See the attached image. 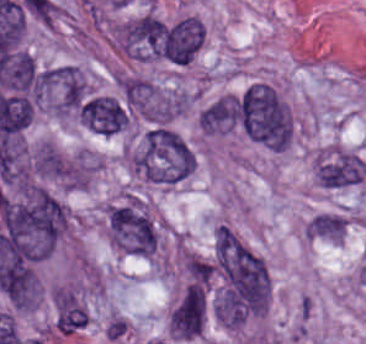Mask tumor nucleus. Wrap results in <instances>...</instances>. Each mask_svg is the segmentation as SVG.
<instances>
[{
	"label": "tumor nucleus",
	"mask_w": 366,
	"mask_h": 344,
	"mask_svg": "<svg viewBox=\"0 0 366 344\" xmlns=\"http://www.w3.org/2000/svg\"><path fill=\"white\" fill-rule=\"evenodd\" d=\"M235 121L249 139L271 150H285L292 135L291 110L271 84L255 82L235 98Z\"/></svg>",
	"instance_id": "tumor-nucleus-1"
},
{
	"label": "tumor nucleus",
	"mask_w": 366,
	"mask_h": 344,
	"mask_svg": "<svg viewBox=\"0 0 366 344\" xmlns=\"http://www.w3.org/2000/svg\"><path fill=\"white\" fill-rule=\"evenodd\" d=\"M129 168L153 183L174 184L190 174L193 152L166 126L154 125L127 155Z\"/></svg>",
	"instance_id": "tumor-nucleus-2"
},
{
	"label": "tumor nucleus",
	"mask_w": 366,
	"mask_h": 344,
	"mask_svg": "<svg viewBox=\"0 0 366 344\" xmlns=\"http://www.w3.org/2000/svg\"><path fill=\"white\" fill-rule=\"evenodd\" d=\"M79 122L89 131L111 136L127 125L126 111L113 96L91 94L79 104Z\"/></svg>",
	"instance_id": "tumor-nucleus-3"
},
{
	"label": "tumor nucleus",
	"mask_w": 366,
	"mask_h": 344,
	"mask_svg": "<svg viewBox=\"0 0 366 344\" xmlns=\"http://www.w3.org/2000/svg\"><path fill=\"white\" fill-rule=\"evenodd\" d=\"M164 41L169 60L183 66L194 59L202 45V24L193 15H186L165 29Z\"/></svg>",
	"instance_id": "tumor-nucleus-4"
}]
</instances>
